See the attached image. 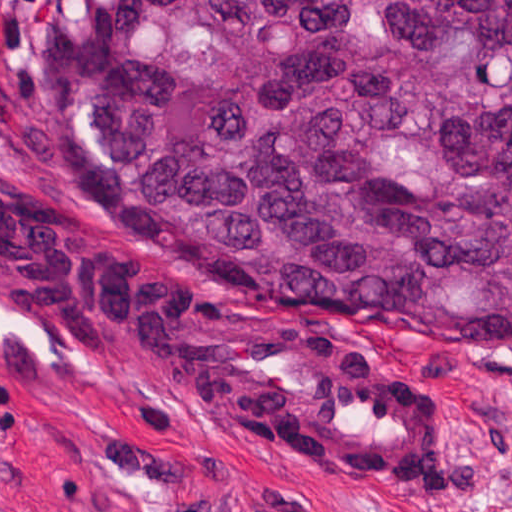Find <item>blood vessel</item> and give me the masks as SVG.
<instances>
[{
	"label": "blood vessel",
	"mask_w": 512,
	"mask_h": 512,
	"mask_svg": "<svg viewBox=\"0 0 512 512\" xmlns=\"http://www.w3.org/2000/svg\"><path fill=\"white\" fill-rule=\"evenodd\" d=\"M0 308L113 384L323 470L411 495L453 483L433 383L347 311L267 302L2 176Z\"/></svg>",
	"instance_id": "obj_1"
}]
</instances>
